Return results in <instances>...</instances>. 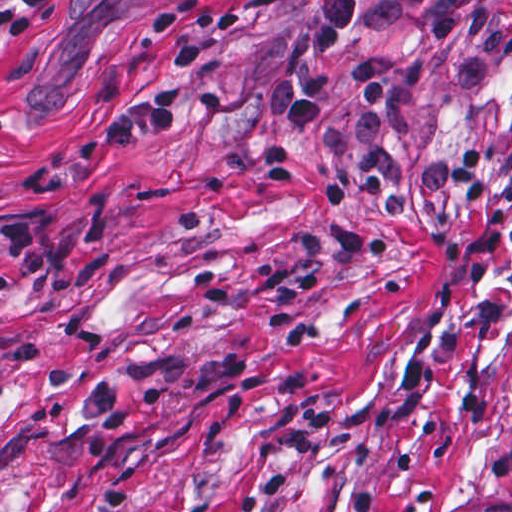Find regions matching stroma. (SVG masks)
Here are the masks:
<instances>
[{
	"label": "stroma",
	"instance_id": "obj_1",
	"mask_svg": "<svg viewBox=\"0 0 512 512\" xmlns=\"http://www.w3.org/2000/svg\"><path fill=\"white\" fill-rule=\"evenodd\" d=\"M183 1L0 0V224L52 247L0 299V512L512 508V52L474 87L452 40L404 91L399 146L478 154L476 209L316 202L360 62L421 32L344 36L287 135L262 86L308 0H198L246 12L225 45L188 34L184 89L223 113L38 190L168 83L150 22Z\"/></svg>",
	"mask_w": 512,
	"mask_h": 512
}]
</instances>
